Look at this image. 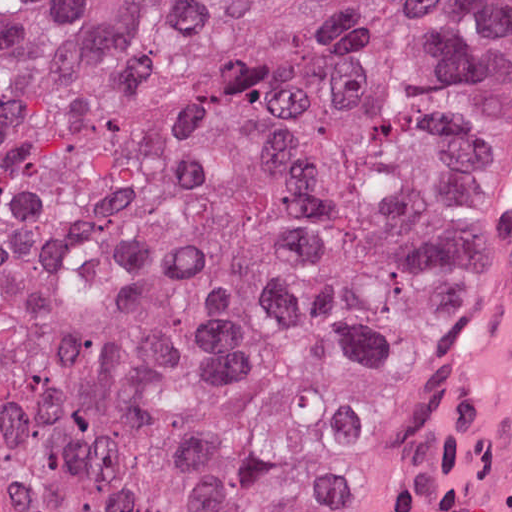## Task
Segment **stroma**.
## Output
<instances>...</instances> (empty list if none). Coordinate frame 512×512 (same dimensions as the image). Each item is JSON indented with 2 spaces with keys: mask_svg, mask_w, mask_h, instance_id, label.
Wrapping results in <instances>:
<instances>
[{
  "mask_svg": "<svg viewBox=\"0 0 512 512\" xmlns=\"http://www.w3.org/2000/svg\"><path fill=\"white\" fill-rule=\"evenodd\" d=\"M512 301V219L484 285L435 355L423 381L351 455L319 512H377L432 425L476 379Z\"/></svg>",
  "mask_w": 512,
  "mask_h": 512,
  "instance_id": "1",
  "label": "stroma"
}]
</instances>
